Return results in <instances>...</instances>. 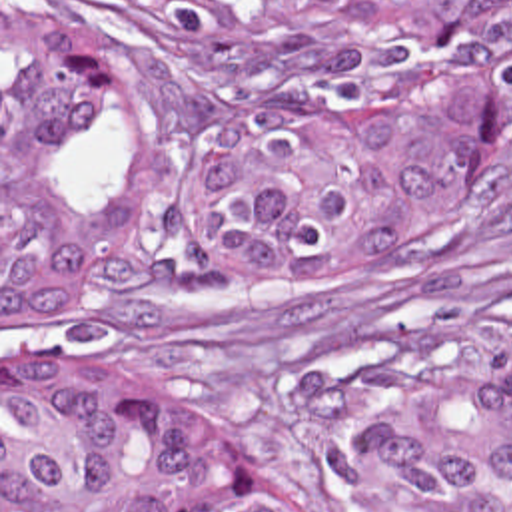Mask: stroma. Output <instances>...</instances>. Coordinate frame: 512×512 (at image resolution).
<instances>
[{
  "instance_id": "obj_1",
  "label": "stroma",
  "mask_w": 512,
  "mask_h": 512,
  "mask_svg": "<svg viewBox=\"0 0 512 512\" xmlns=\"http://www.w3.org/2000/svg\"><path fill=\"white\" fill-rule=\"evenodd\" d=\"M42 2L124 46L144 88L220 98L124 6ZM72 183L102 235L100 289L76 313L2 329L0 0V512L2 369L174 399L252 473L351 512L347 461L381 387L455 377L512 347V139L429 253L349 285H236L204 265L186 155L150 143L118 90L90 98Z\"/></svg>"
}]
</instances>
